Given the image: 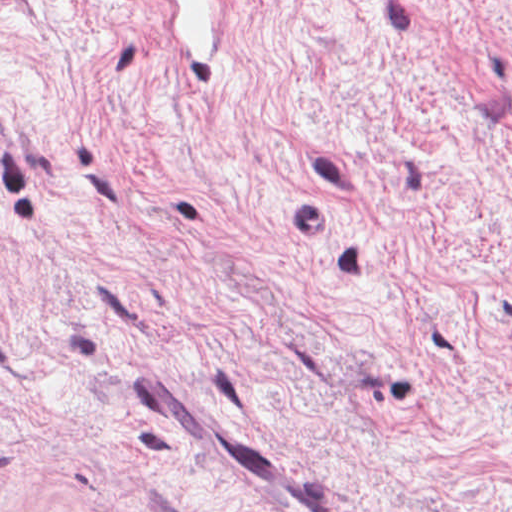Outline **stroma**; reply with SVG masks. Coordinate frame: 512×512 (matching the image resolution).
Masks as SVG:
<instances>
[{
  "mask_svg": "<svg viewBox=\"0 0 512 512\" xmlns=\"http://www.w3.org/2000/svg\"><path fill=\"white\" fill-rule=\"evenodd\" d=\"M0 512H512V0H0Z\"/></svg>",
  "mask_w": 512,
  "mask_h": 512,
  "instance_id": "stroma-1",
  "label": "stroma"
}]
</instances>
